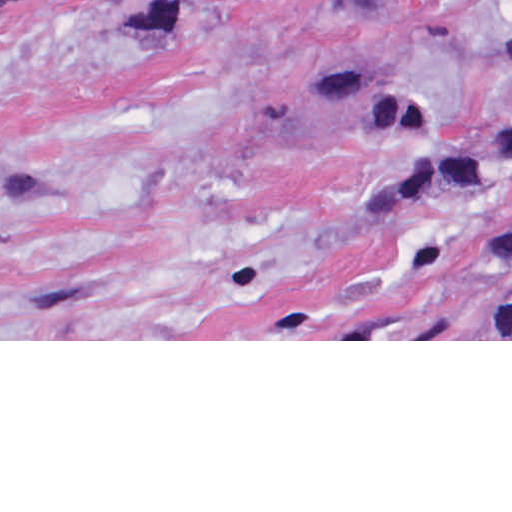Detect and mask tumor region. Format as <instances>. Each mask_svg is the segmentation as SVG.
<instances>
[{
	"label": "tumor region",
	"mask_w": 512,
	"mask_h": 512,
	"mask_svg": "<svg viewBox=\"0 0 512 512\" xmlns=\"http://www.w3.org/2000/svg\"><path fill=\"white\" fill-rule=\"evenodd\" d=\"M498 42L512 56V0L507 1L498 25ZM421 118L422 104L410 93L382 140L413 127ZM414 162H512V124L460 143L443 154ZM422 339H512V263L480 298Z\"/></svg>",
	"instance_id": "e687c5a6"
}]
</instances>
